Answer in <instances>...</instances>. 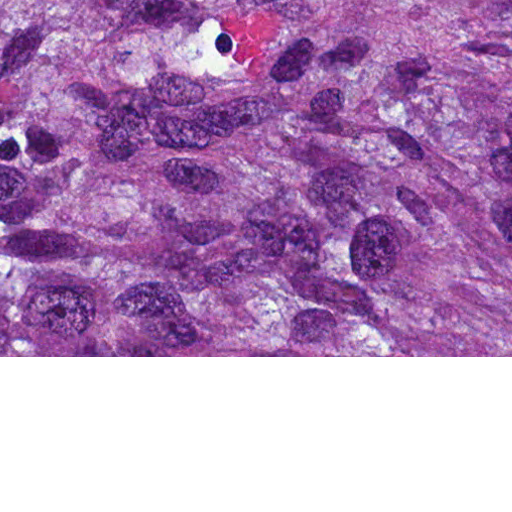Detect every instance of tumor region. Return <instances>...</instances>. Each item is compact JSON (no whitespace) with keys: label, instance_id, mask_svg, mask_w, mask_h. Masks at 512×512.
<instances>
[{"label":"tumor region","instance_id":"e687c5a6","mask_svg":"<svg viewBox=\"0 0 512 512\" xmlns=\"http://www.w3.org/2000/svg\"><path fill=\"white\" fill-rule=\"evenodd\" d=\"M0 356H512V0H0Z\"/></svg>","mask_w":512,"mask_h":512}]
</instances>
